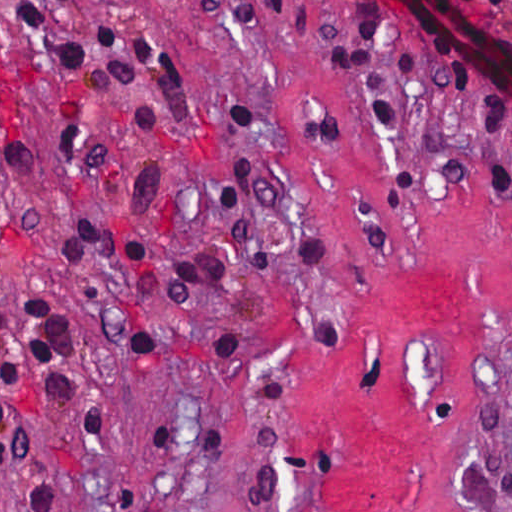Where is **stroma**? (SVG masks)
I'll list each match as a JSON object with an SVG mask.
<instances>
[{
    "label": "stroma",
    "instance_id": "stroma-1",
    "mask_svg": "<svg viewBox=\"0 0 512 512\" xmlns=\"http://www.w3.org/2000/svg\"><path fill=\"white\" fill-rule=\"evenodd\" d=\"M21 1L0 0V512H512V204L480 186L431 25L311 0L395 64L391 131L267 0H108L184 67L183 112L152 140L28 44ZM437 1L512 45L511 15ZM148 160L157 259L216 248L214 192L248 160L262 242L322 240L339 272H231L189 304L157 276L138 306L136 276L56 235L122 228ZM151 329L240 354L151 351Z\"/></svg>",
    "mask_w": 512,
    "mask_h": 512
}]
</instances>
